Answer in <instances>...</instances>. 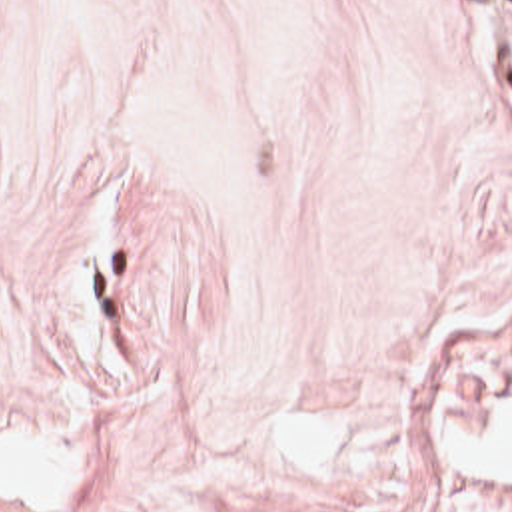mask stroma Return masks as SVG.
I'll return each mask as SVG.
<instances>
[{
    "instance_id": "obj_1",
    "label": "stroma",
    "mask_w": 512,
    "mask_h": 512,
    "mask_svg": "<svg viewBox=\"0 0 512 512\" xmlns=\"http://www.w3.org/2000/svg\"><path fill=\"white\" fill-rule=\"evenodd\" d=\"M0 512H512V0H0Z\"/></svg>"
}]
</instances>
